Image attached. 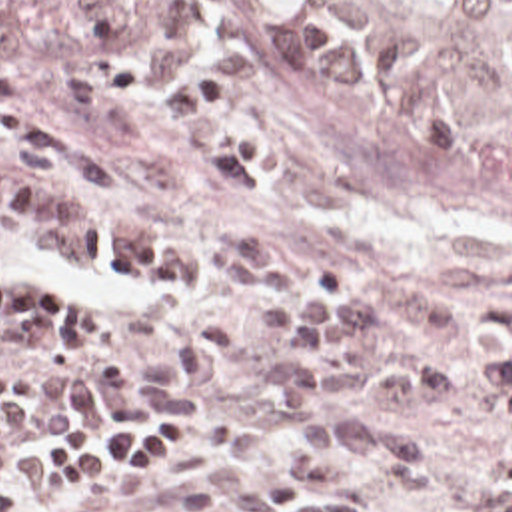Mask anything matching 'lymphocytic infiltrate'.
Here are the masks:
<instances>
[{
    "mask_svg": "<svg viewBox=\"0 0 512 512\" xmlns=\"http://www.w3.org/2000/svg\"><path fill=\"white\" fill-rule=\"evenodd\" d=\"M103 39L95 75L87 81L71 63L63 91L83 113L113 105L121 91L143 79L139 39L173 67V111L201 143L217 177L245 199H263L271 179L255 173L265 137L221 121L225 81L179 61L163 41L161 0H73ZM211 281L247 297L253 327L273 335L271 379L275 397L299 411H319L343 395L381 403L413 419L431 401H469L499 421L495 467L512 481V333L481 359H401L419 293L403 285L349 287L315 263H285L257 235L241 227L217 237ZM63 323V283L55 279H0V343H27ZM397 421L395 425L407 423ZM179 449V427L119 435H43L39 473L47 485L99 479L135 485L153 477ZM29 471V435L0 439V512H17V483ZM65 512H113L83 501ZM137 512H199L163 501Z\"/></svg>",
    "mask_w": 512,
    "mask_h": 512,
    "instance_id": "f902f5d3",
    "label": "lymphocytic infiltrate"
}]
</instances>
